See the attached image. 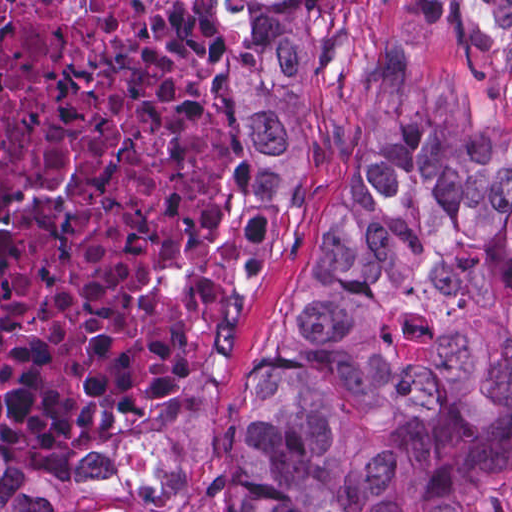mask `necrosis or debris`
<instances>
[{
    "label": "necrosis or debris",
    "instance_id": "4bbe7bcc",
    "mask_svg": "<svg viewBox=\"0 0 512 512\" xmlns=\"http://www.w3.org/2000/svg\"><path fill=\"white\" fill-rule=\"evenodd\" d=\"M228 157L191 0H0V421L98 452L195 363Z\"/></svg>",
    "mask_w": 512,
    "mask_h": 512
}]
</instances>
